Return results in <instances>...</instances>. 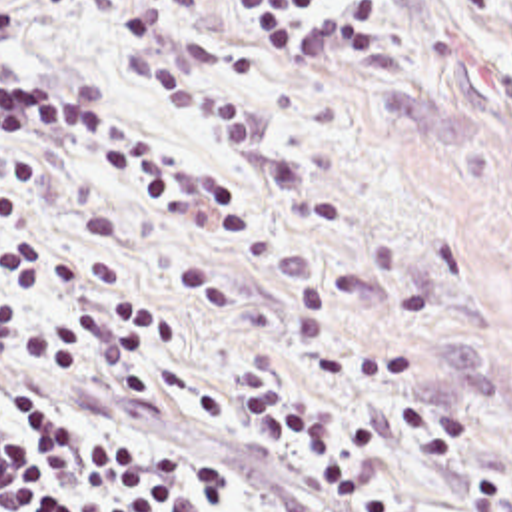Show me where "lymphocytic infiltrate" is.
I'll return each mask as SVG.
<instances>
[{
	"label": "lymphocytic infiltrate",
	"mask_w": 512,
	"mask_h": 512,
	"mask_svg": "<svg viewBox=\"0 0 512 512\" xmlns=\"http://www.w3.org/2000/svg\"><path fill=\"white\" fill-rule=\"evenodd\" d=\"M224 0H134L118 33L120 59L138 89L238 145L262 139L258 93L220 85L192 59L182 21ZM258 51L314 53L336 45L334 0H230ZM66 115L112 143L140 171L156 201L176 215H212L220 167H206L164 133L80 99L42 73L0 63V119ZM24 219V203L0 197V233ZM0 338L52 366L94 372L116 388H146L148 348L170 352L176 326L142 301L90 305L52 316L38 303L56 283H114L118 267L78 261L32 239L0 241ZM236 400L252 434L268 446L302 448L332 498H358L372 456V426L356 414L328 416L266 368H234ZM0 512H238L228 472L184 440L144 432L78 404L0 358Z\"/></svg>",
	"instance_id": "lymphocytic-infiltrate-1"
}]
</instances>
